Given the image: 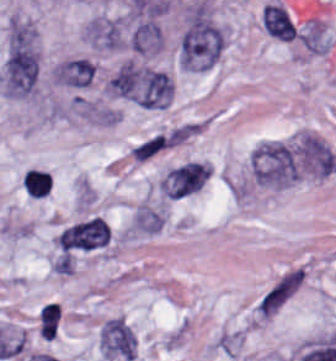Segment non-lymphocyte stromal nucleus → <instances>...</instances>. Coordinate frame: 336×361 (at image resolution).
Instances as JSON below:
<instances>
[{"label": "non-lymphocyte stromal nucleus", "instance_id": "2", "mask_svg": "<svg viewBox=\"0 0 336 361\" xmlns=\"http://www.w3.org/2000/svg\"><path fill=\"white\" fill-rule=\"evenodd\" d=\"M224 33L210 7L200 2L189 9L178 45L183 68L189 71H208L222 54Z\"/></svg>", "mask_w": 336, "mask_h": 361}, {"label": "non-lymphocyte stromal nucleus", "instance_id": "1", "mask_svg": "<svg viewBox=\"0 0 336 361\" xmlns=\"http://www.w3.org/2000/svg\"><path fill=\"white\" fill-rule=\"evenodd\" d=\"M39 53L36 33L25 20H12L3 59L1 85L12 98L28 97L36 87Z\"/></svg>", "mask_w": 336, "mask_h": 361}, {"label": "non-lymphocyte stromal nucleus", "instance_id": "11", "mask_svg": "<svg viewBox=\"0 0 336 361\" xmlns=\"http://www.w3.org/2000/svg\"><path fill=\"white\" fill-rule=\"evenodd\" d=\"M130 50L148 54L162 50L163 37L155 18H147L135 26L129 36Z\"/></svg>", "mask_w": 336, "mask_h": 361}, {"label": "non-lymphocyte stromal nucleus", "instance_id": "4", "mask_svg": "<svg viewBox=\"0 0 336 361\" xmlns=\"http://www.w3.org/2000/svg\"><path fill=\"white\" fill-rule=\"evenodd\" d=\"M251 174L263 186L281 188L294 182L298 172L295 146L279 140H266L250 154Z\"/></svg>", "mask_w": 336, "mask_h": 361}, {"label": "non-lymphocyte stromal nucleus", "instance_id": "6", "mask_svg": "<svg viewBox=\"0 0 336 361\" xmlns=\"http://www.w3.org/2000/svg\"><path fill=\"white\" fill-rule=\"evenodd\" d=\"M99 340L105 358L121 361L135 358L134 334L123 317L107 320L99 332Z\"/></svg>", "mask_w": 336, "mask_h": 361}, {"label": "non-lymphocyte stromal nucleus", "instance_id": "9", "mask_svg": "<svg viewBox=\"0 0 336 361\" xmlns=\"http://www.w3.org/2000/svg\"><path fill=\"white\" fill-rule=\"evenodd\" d=\"M85 37L89 45L102 50L126 47L121 23L115 18H94L88 22Z\"/></svg>", "mask_w": 336, "mask_h": 361}, {"label": "non-lymphocyte stromal nucleus", "instance_id": "8", "mask_svg": "<svg viewBox=\"0 0 336 361\" xmlns=\"http://www.w3.org/2000/svg\"><path fill=\"white\" fill-rule=\"evenodd\" d=\"M207 174L208 164L188 161L166 174L162 191L168 198L182 199L200 190Z\"/></svg>", "mask_w": 336, "mask_h": 361}, {"label": "non-lymphocyte stromal nucleus", "instance_id": "3", "mask_svg": "<svg viewBox=\"0 0 336 361\" xmlns=\"http://www.w3.org/2000/svg\"><path fill=\"white\" fill-rule=\"evenodd\" d=\"M118 97L147 110H162L172 99V82L162 72L124 65L109 81Z\"/></svg>", "mask_w": 336, "mask_h": 361}, {"label": "non-lymphocyte stromal nucleus", "instance_id": "7", "mask_svg": "<svg viewBox=\"0 0 336 361\" xmlns=\"http://www.w3.org/2000/svg\"><path fill=\"white\" fill-rule=\"evenodd\" d=\"M110 238L109 226L97 217L66 229L61 234L59 243L62 250L90 251L106 246Z\"/></svg>", "mask_w": 336, "mask_h": 361}, {"label": "non-lymphocyte stromal nucleus", "instance_id": "5", "mask_svg": "<svg viewBox=\"0 0 336 361\" xmlns=\"http://www.w3.org/2000/svg\"><path fill=\"white\" fill-rule=\"evenodd\" d=\"M306 273L301 265L284 270L257 298L254 315L271 319L301 288Z\"/></svg>", "mask_w": 336, "mask_h": 361}, {"label": "non-lymphocyte stromal nucleus", "instance_id": "10", "mask_svg": "<svg viewBox=\"0 0 336 361\" xmlns=\"http://www.w3.org/2000/svg\"><path fill=\"white\" fill-rule=\"evenodd\" d=\"M96 73L97 67L94 62L84 57H77L58 65L54 72V78L57 84L79 89L89 87L93 83Z\"/></svg>", "mask_w": 336, "mask_h": 361}]
</instances>
